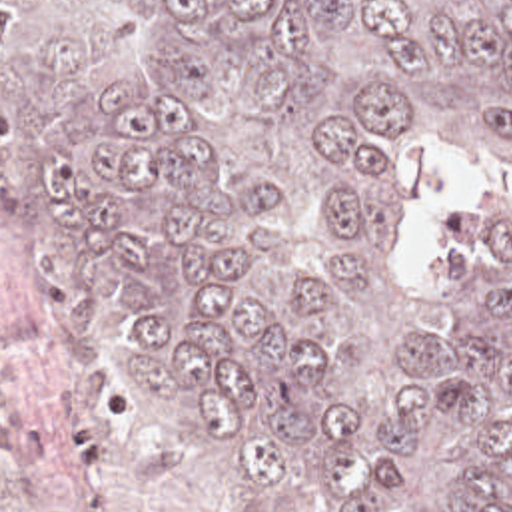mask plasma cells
<instances>
[{
	"instance_id": "obj_1",
	"label": "plasma cells",
	"mask_w": 512,
	"mask_h": 512,
	"mask_svg": "<svg viewBox=\"0 0 512 512\" xmlns=\"http://www.w3.org/2000/svg\"><path fill=\"white\" fill-rule=\"evenodd\" d=\"M54 333L40 317H8L0 321V468L18 474L34 466L46 452L44 438L16 414L22 406L18 380L34 361L52 353ZM22 512H74L32 506Z\"/></svg>"
}]
</instances>
